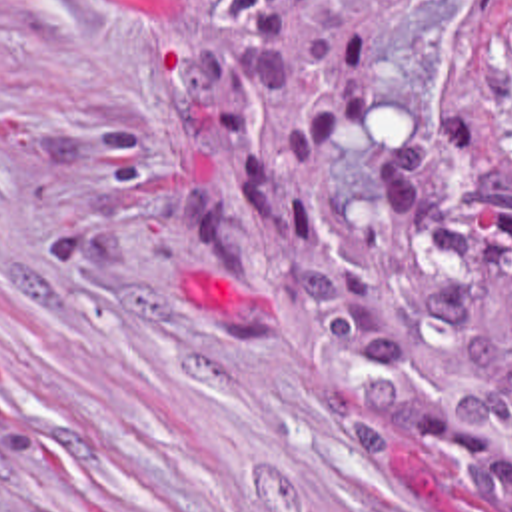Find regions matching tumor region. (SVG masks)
<instances>
[{
	"label": "tumor region",
	"mask_w": 512,
	"mask_h": 512,
	"mask_svg": "<svg viewBox=\"0 0 512 512\" xmlns=\"http://www.w3.org/2000/svg\"><path fill=\"white\" fill-rule=\"evenodd\" d=\"M174 66L230 132L246 234L398 370L428 376L486 418H512V0L492 1L498 130L440 106L346 242H310L324 142L362 130L392 17L420 0H142ZM356 412L432 464L478 478L512 512V450L456 400L376 368L348 372Z\"/></svg>",
	"instance_id": "e687c5a6"
}]
</instances>
